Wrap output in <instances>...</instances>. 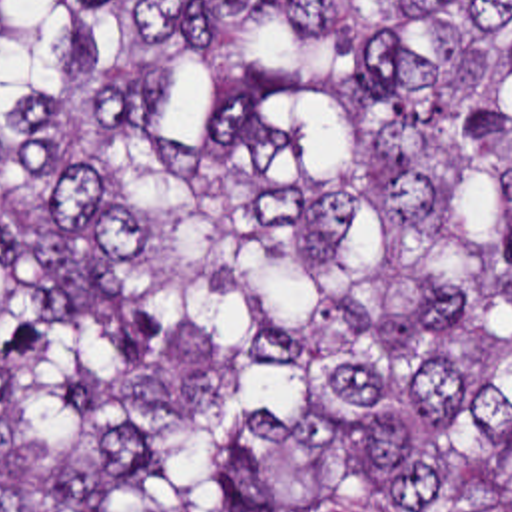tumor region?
<instances>
[{
  "instance_id": "1",
  "label": "tumor region",
  "mask_w": 512,
  "mask_h": 512,
  "mask_svg": "<svg viewBox=\"0 0 512 512\" xmlns=\"http://www.w3.org/2000/svg\"><path fill=\"white\" fill-rule=\"evenodd\" d=\"M0 512H512V0H0Z\"/></svg>"
}]
</instances>
